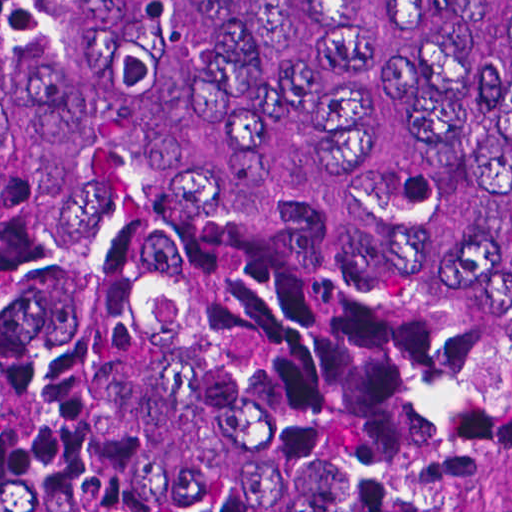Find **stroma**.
Wrapping results in <instances>:
<instances>
[{
  "label": "stroma",
  "mask_w": 512,
  "mask_h": 512,
  "mask_svg": "<svg viewBox=\"0 0 512 512\" xmlns=\"http://www.w3.org/2000/svg\"><path fill=\"white\" fill-rule=\"evenodd\" d=\"M396 512H512V494H445Z\"/></svg>",
  "instance_id": "35a3bbf8"
}]
</instances>
